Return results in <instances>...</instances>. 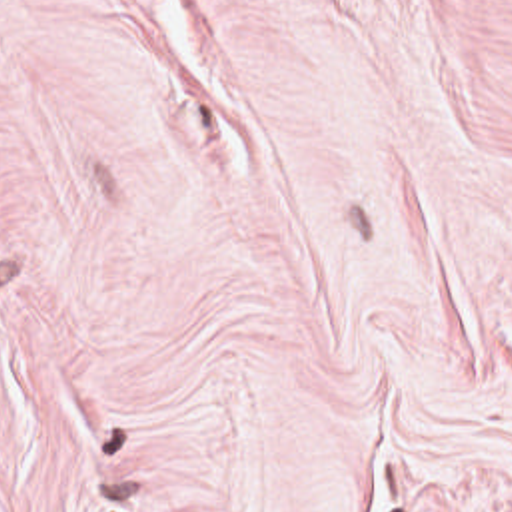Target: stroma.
Masks as SVG:
<instances>
[{"label": "stroma", "instance_id": "35a3bbf8", "mask_svg": "<svg viewBox=\"0 0 512 512\" xmlns=\"http://www.w3.org/2000/svg\"><path fill=\"white\" fill-rule=\"evenodd\" d=\"M0 512H512V0H0Z\"/></svg>", "mask_w": 512, "mask_h": 512}]
</instances>
